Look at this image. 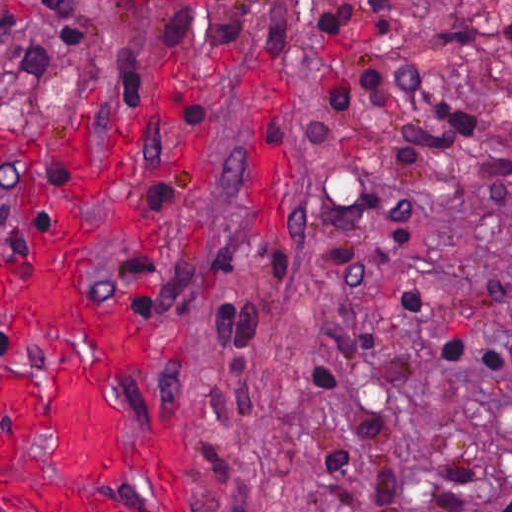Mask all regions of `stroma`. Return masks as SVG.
Returning <instances> with one entry per match:
<instances>
[{
    "instance_id": "1",
    "label": "stroma",
    "mask_w": 512,
    "mask_h": 512,
    "mask_svg": "<svg viewBox=\"0 0 512 512\" xmlns=\"http://www.w3.org/2000/svg\"><path fill=\"white\" fill-rule=\"evenodd\" d=\"M394 45L512 153V0H396ZM88 125L141 134L157 183L153 247L102 243L100 262L160 307L150 392L200 441V512H322L312 362L397 288L506 350L475 377L406 352L381 439L404 512H431L455 448L481 501L512 498V223L409 171L402 208L425 237L375 224L362 277L329 266L308 128L362 131L306 0H0V284L57 145Z\"/></svg>"
}]
</instances>
